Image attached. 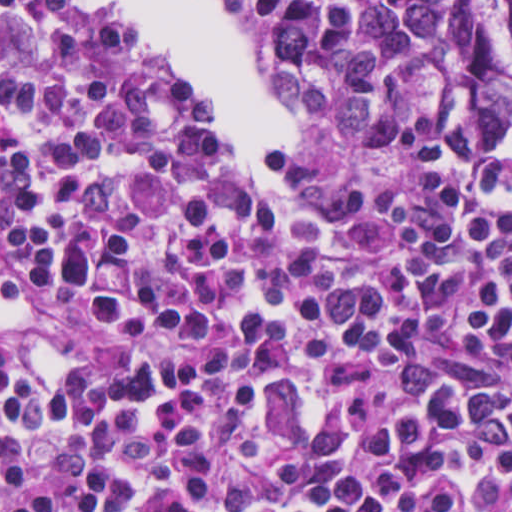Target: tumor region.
<instances>
[{
    "label": "tumor region",
    "mask_w": 512,
    "mask_h": 512,
    "mask_svg": "<svg viewBox=\"0 0 512 512\" xmlns=\"http://www.w3.org/2000/svg\"><path fill=\"white\" fill-rule=\"evenodd\" d=\"M283 105L340 140L484 144L512 117V0H223Z\"/></svg>",
    "instance_id": "e687c5a6"
}]
</instances>
